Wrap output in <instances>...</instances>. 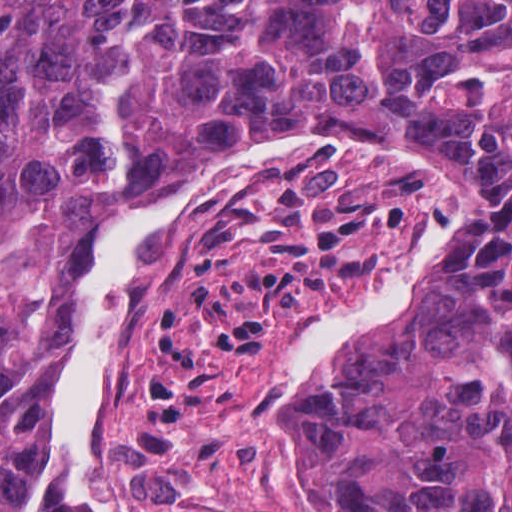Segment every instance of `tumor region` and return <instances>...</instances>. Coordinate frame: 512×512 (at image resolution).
I'll return each instance as SVG.
<instances>
[{
  "label": "tumor region",
  "mask_w": 512,
  "mask_h": 512,
  "mask_svg": "<svg viewBox=\"0 0 512 512\" xmlns=\"http://www.w3.org/2000/svg\"><path fill=\"white\" fill-rule=\"evenodd\" d=\"M327 135L452 148L484 229L344 342L332 411L387 512H512V0H0V500L26 337L85 239L188 165ZM26 512H74L36 495Z\"/></svg>",
  "instance_id": "tumor-region-1"
}]
</instances>
